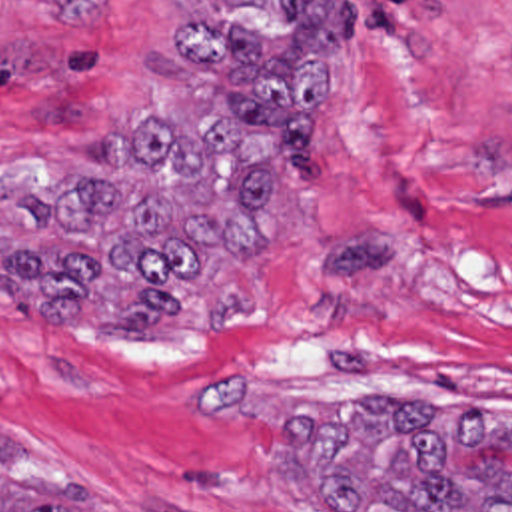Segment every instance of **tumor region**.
Instances as JSON below:
<instances>
[{
  "mask_svg": "<svg viewBox=\"0 0 512 512\" xmlns=\"http://www.w3.org/2000/svg\"><path fill=\"white\" fill-rule=\"evenodd\" d=\"M51 4L59 0H47ZM171 46L197 92L189 110L141 116L125 156L155 178L129 200L107 174H69L23 200L27 236L0 248V284L33 320L177 322L221 258L273 248L265 200L315 184L327 70L345 46V0H211ZM323 512H512V475L462 473L466 445H512L492 405L363 395L349 413L301 411L279 431ZM49 449L0 427V512H65Z\"/></svg>",
  "mask_w": 512,
  "mask_h": 512,
  "instance_id": "e687c5a6",
  "label": "tumor region"
}]
</instances>
